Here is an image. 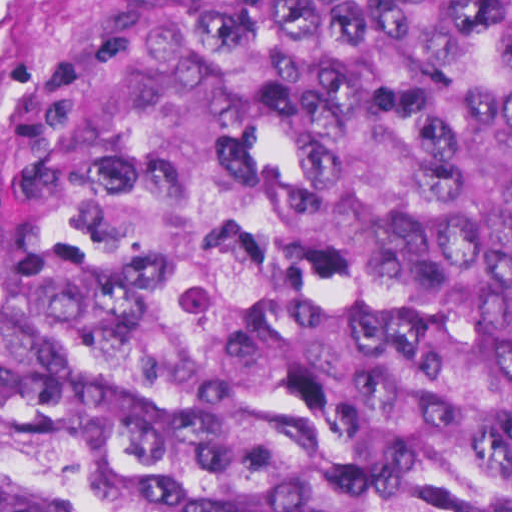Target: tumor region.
Listing matches in <instances>:
<instances>
[{
  "label": "tumor region",
  "mask_w": 512,
  "mask_h": 512,
  "mask_svg": "<svg viewBox=\"0 0 512 512\" xmlns=\"http://www.w3.org/2000/svg\"><path fill=\"white\" fill-rule=\"evenodd\" d=\"M0 512H512V0H146L0 180Z\"/></svg>",
  "instance_id": "1"
}]
</instances>
